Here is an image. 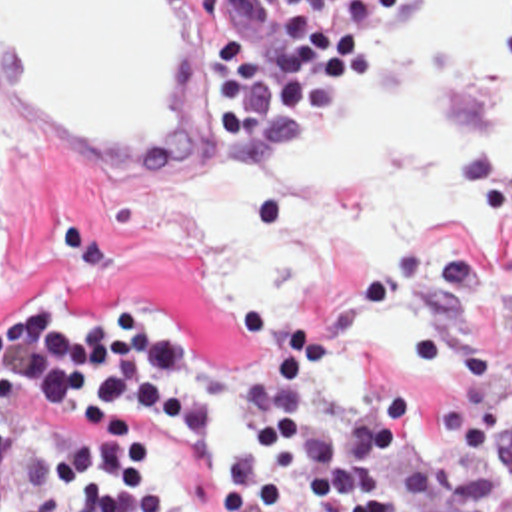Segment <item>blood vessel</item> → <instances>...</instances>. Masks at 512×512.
<instances>
[{
  "label": "blood vessel",
  "instance_id": "blood-vessel-1",
  "mask_svg": "<svg viewBox=\"0 0 512 512\" xmlns=\"http://www.w3.org/2000/svg\"><path fill=\"white\" fill-rule=\"evenodd\" d=\"M219 0H0V105L139 173L189 157Z\"/></svg>",
  "mask_w": 512,
  "mask_h": 512
}]
</instances>
